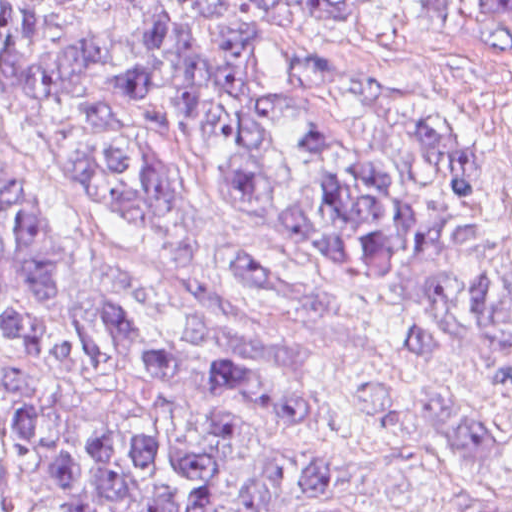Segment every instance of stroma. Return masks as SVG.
<instances>
[{
	"label": "stroma",
	"mask_w": 512,
	"mask_h": 512,
	"mask_svg": "<svg viewBox=\"0 0 512 512\" xmlns=\"http://www.w3.org/2000/svg\"><path fill=\"white\" fill-rule=\"evenodd\" d=\"M349 20L260 0H218L203 13L207 36L251 39L253 75L279 81L298 51L335 55L333 74L374 102L437 117L467 134L512 194V0H332ZM67 25L95 52L100 87L126 141L167 163L179 204L163 231L135 202L70 181L42 165L0 122V166L32 178L67 215L94 268L134 280L178 306L196 334L294 374L328 427L334 477L360 505L397 512H512V389L492 388L462 349L424 355L406 340L413 283L360 287L308 244L273 236L220 190L209 151L158 98L124 99L118 84L138 43L125 0H58ZM245 249L272 269L261 305L207 274L226 250ZM44 428L0 512H67L55 481L72 447L115 431L188 444L226 415L284 450L306 452L312 433L184 383L165 405L150 378L126 369L32 377ZM476 414L500 433V464L458 511L449 501L461 445L454 418ZM7 419L0 399V438ZM259 473L255 457L229 461L213 512H240Z\"/></svg>",
	"instance_id": "1"
}]
</instances>
